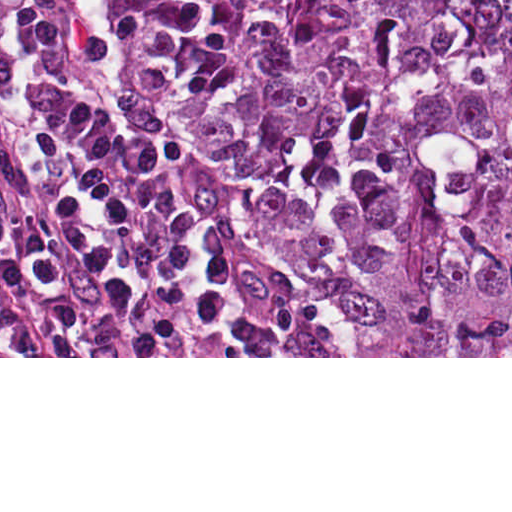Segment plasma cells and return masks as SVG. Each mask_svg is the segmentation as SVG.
Wrapping results in <instances>:
<instances>
[{
    "label": "plasma cells",
    "instance_id": "9512152a",
    "mask_svg": "<svg viewBox=\"0 0 512 512\" xmlns=\"http://www.w3.org/2000/svg\"><path fill=\"white\" fill-rule=\"evenodd\" d=\"M0 356H343L226 182L100 107L87 0H0Z\"/></svg>",
    "mask_w": 512,
    "mask_h": 512
}]
</instances>
